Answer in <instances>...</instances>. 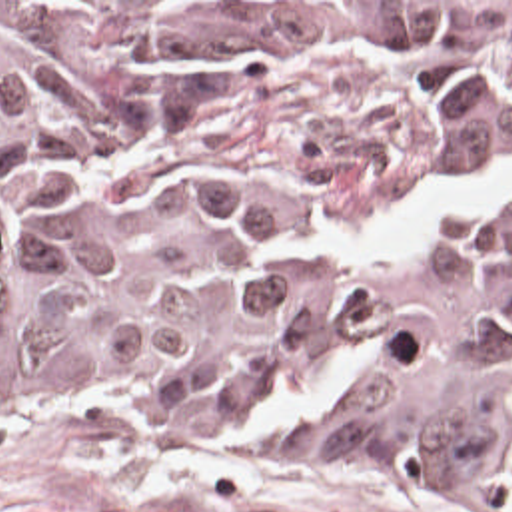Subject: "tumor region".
I'll return each instance as SVG.
<instances>
[{"label": "tumor region", "mask_w": 512, "mask_h": 512, "mask_svg": "<svg viewBox=\"0 0 512 512\" xmlns=\"http://www.w3.org/2000/svg\"><path fill=\"white\" fill-rule=\"evenodd\" d=\"M512 2H0V435L512 495Z\"/></svg>", "instance_id": "tumor-region-1"}]
</instances>
